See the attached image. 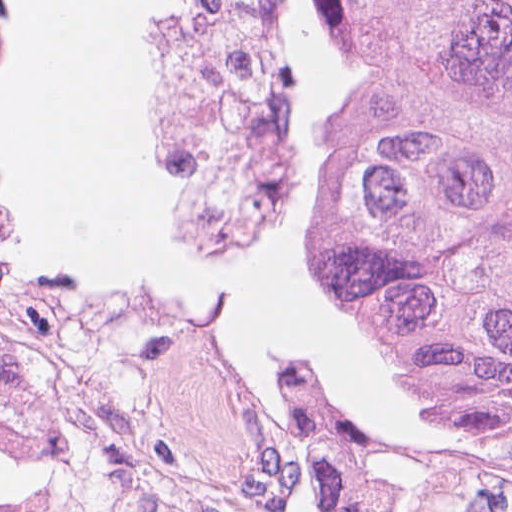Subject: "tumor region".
<instances>
[{
	"label": "tumor region",
	"mask_w": 512,
	"mask_h": 512,
	"mask_svg": "<svg viewBox=\"0 0 512 512\" xmlns=\"http://www.w3.org/2000/svg\"><path fill=\"white\" fill-rule=\"evenodd\" d=\"M25 38L20 0H0V55ZM337 54L345 116L321 250L342 311L369 357L512 453V0H337ZM72 380L88 423L177 426L237 459L135 370L61 381L0 320V398L56 402L60 419Z\"/></svg>",
	"instance_id": "e687c5a6"
}]
</instances>
